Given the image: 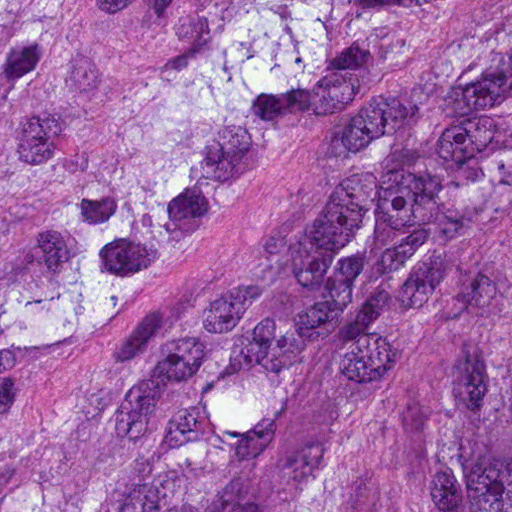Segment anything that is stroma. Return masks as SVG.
<instances>
[{"instance_id":"35a3bbf8","label":"stroma","mask_w":512,"mask_h":512,"mask_svg":"<svg viewBox=\"0 0 512 512\" xmlns=\"http://www.w3.org/2000/svg\"><path fill=\"white\" fill-rule=\"evenodd\" d=\"M103 0H22L0 100V254L40 223L45 204L23 167L25 147L55 91L100 59Z\"/></svg>"}]
</instances>
